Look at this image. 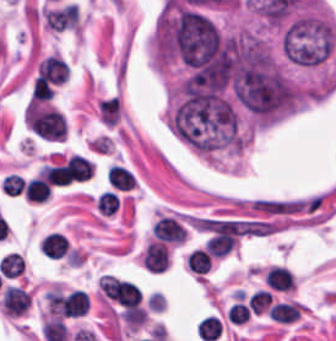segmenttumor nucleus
<instances>
[{
  "label": "tumor nucleus",
  "instance_id": "tumor-nucleus-1",
  "mask_svg": "<svg viewBox=\"0 0 336 341\" xmlns=\"http://www.w3.org/2000/svg\"><path fill=\"white\" fill-rule=\"evenodd\" d=\"M335 46V27L318 11H305L292 17L279 38L282 57L301 66L324 64Z\"/></svg>",
  "mask_w": 336,
  "mask_h": 341
}]
</instances>
